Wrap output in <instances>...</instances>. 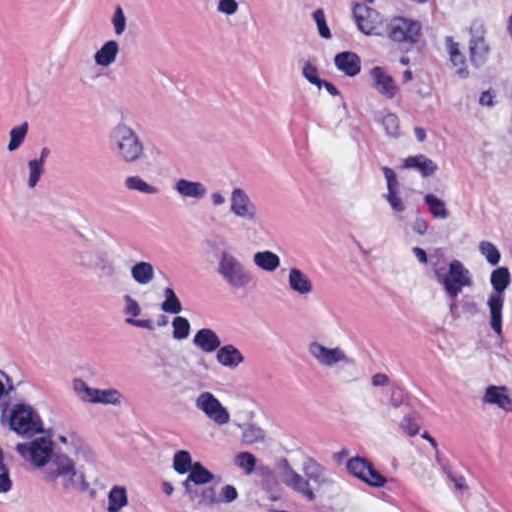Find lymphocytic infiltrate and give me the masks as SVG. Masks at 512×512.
<instances>
[{"label":"lymphocytic infiltrate","mask_w":512,"mask_h":512,"mask_svg":"<svg viewBox=\"0 0 512 512\" xmlns=\"http://www.w3.org/2000/svg\"><path fill=\"white\" fill-rule=\"evenodd\" d=\"M453 8H481L486 0H434ZM503 156L512 167V133ZM0 444L27 473L68 488H94L97 460L29 389L0 324Z\"/></svg>","instance_id":"f902f5d3"}]
</instances>
